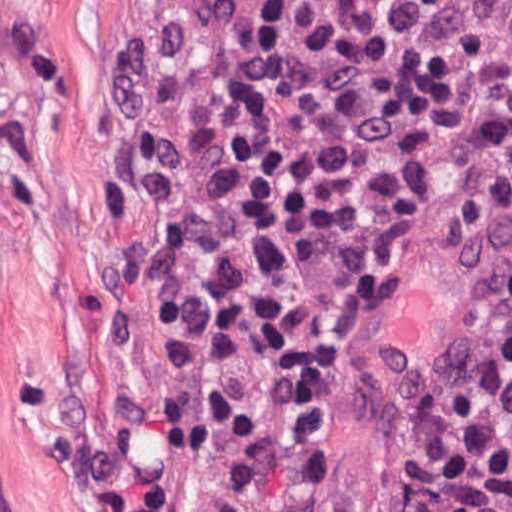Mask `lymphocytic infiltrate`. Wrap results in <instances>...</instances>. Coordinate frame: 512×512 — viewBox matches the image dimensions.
Wrapping results in <instances>:
<instances>
[{
  "mask_svg": "<svg viewBox=\"0 0 512 512\" xmlns=\"http://www.w3.org/2000/svg\"><path fill=\"white\" fill-rule=\"evenodd\" d=\"M466 0H171L118 93L114 206L177 364L118 512H319L359 314L439 162ZM512 284L416 512H498Z\"/></svg>",
  "mask_w": 512,
  "mask_h": 512,
  "instance_id": "1",
  "label": "lymphocytic infiltrate"
}]
</instances>
